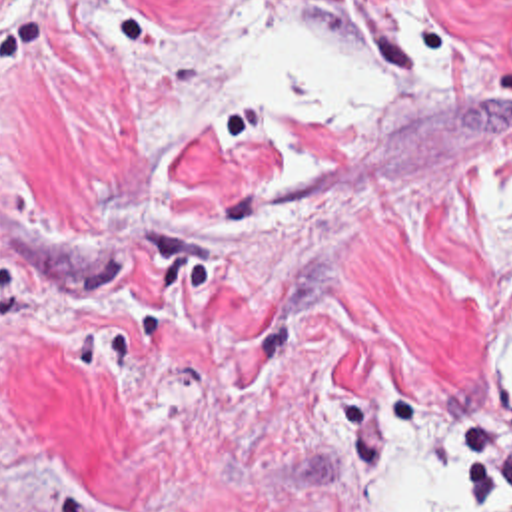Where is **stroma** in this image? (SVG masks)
I'll return each instance as SVG.
<instances>
[{
    "label": "stroma",
    "instance_id": "obj_1",
    "mask_svg": "<svg viewBox=\"0 0 512 512\" xmlns=\"http://www.w3.org/2000/svg\"><path fill=\"white\" fill-rule=\"evenodd\" d=\"M375 399L512 503V0H0V512H381Z\"/></svg>",
    "mask_w": 512,
    "mask_h": 512
}]
</instances>
